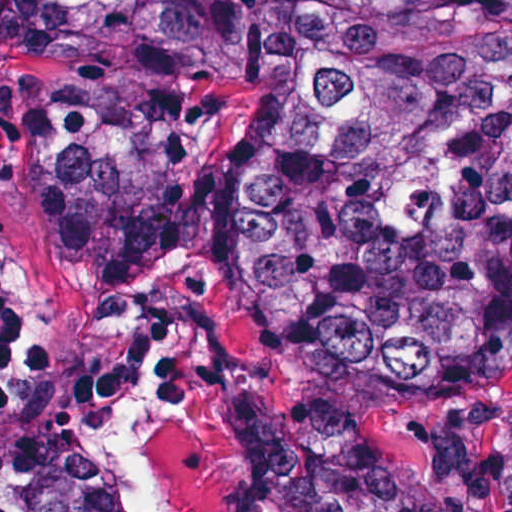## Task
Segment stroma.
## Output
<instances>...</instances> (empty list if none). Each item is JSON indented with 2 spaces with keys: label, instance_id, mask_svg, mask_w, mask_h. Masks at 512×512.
<instances>
[{
  "label": "stroma",
  "instance_id": "obj_1",
  "mask_svg": "<svg viewBox=\"0 0 512 512\" xmlns=\"http://www.w3.org/2000/svg\"><path fill=\"white\" fill-rule=\"evenodd\" d=\"M58 76L57 0H6L0 260L14 329L0 360V448L94 455L91 434L156 345L161 390L182 408L150 450L163 504L238 512L250 488L242 397L272 393L298 409L314 391L299 363L249 324L223 241L230 162L262 106V83L234 81L206 96L189 149L198 226L171 263L148 276L87 275L40 248L57 202ZM511 438L507 385L395 415L381 436L398 461L452 489L458 512H501Z\"/></svg>",
  "mask_w": 512,
  "mask_h": 512
}]
</instances>
